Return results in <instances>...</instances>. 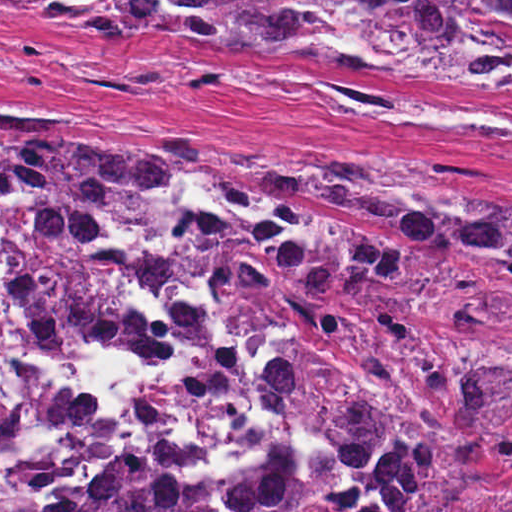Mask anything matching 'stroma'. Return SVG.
<instances>
[{"mask_svg":"<svg viewBox=\"0 0 512 512\" xmlns=\"http://www.w3.org/2000/svg\"><path fill=\"white\" fill-rule=\"evenodd\" d=\"M107 121H134L186 145L184 166L198 178L224 266L253 313L257 368L280 412L260 311L248 277L232 260L195 145L475 174L512 188V94L261 48L147 33L90 37L0 7V128ZM300 439L326 481L329 512H350L351 490L336 464Z\"/></svg>","mask_w":512,"mask_h":512,"instance_id":"1","label":"stroma"}]
</instances>
